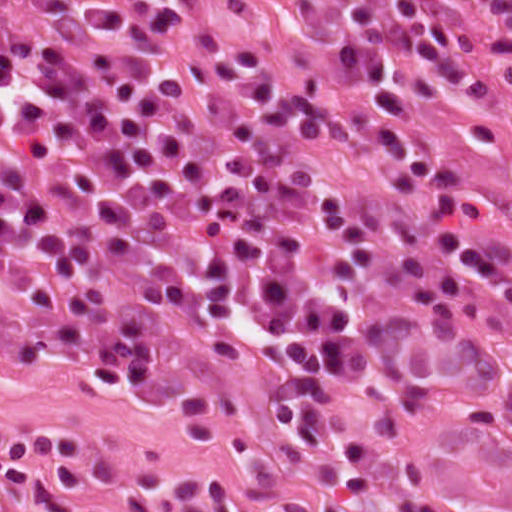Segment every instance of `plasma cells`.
<instances>
[{"instance_id":"9512152a","label":"plasma cells","mask_w":512,"mask_h":512,"mask_svg":"<svg viewBox=\"0 0 512 512\" xmlns=\"http://www.w3.org/2000/svg\"><path fill=\"white\" fill-rule=\"evenodd\" d=\"M467 12L512 84V0H357L365 103L431 107L472 62ZM377 141L390 183L341 112L199 0H0V357L72 361L212 420L228 395L170 328L274 350L292 380L270 403L296 443L333 435L358 493L366 462L391 457L397 512H452L395 421L377 417L368 444L327 391L402 380L464 295L472 351L512 413V277L450 227L488 218L465 169L389 126ZM419 190L429 241L407 205ZM82 439L0 434V512L116 506Z\"/></svg>"}]
</instances>
